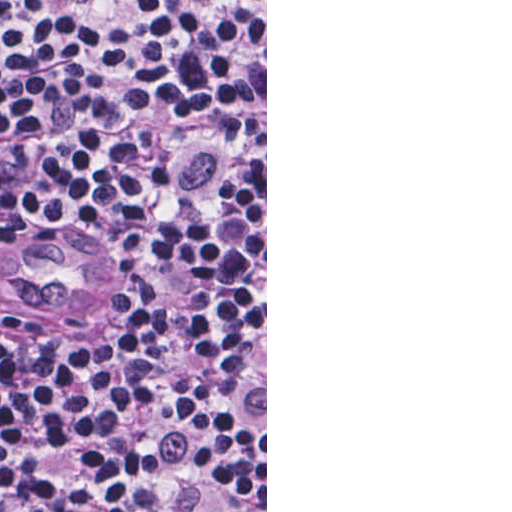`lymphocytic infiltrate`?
Here are the masks:
<instances>
[{"instance_id":"lymphocytic-infiltrate-1","label":"lymphocytic infiltrate","mask_w":512,"mask_h":512,"mask_svg":"<svg viewBox=\"0 0 512 512\" xmlns=\"http://www.w3.org/2000/svg\"><path fill=\"white\" fill-rule=\"evenodd\" d=\"M0 512H265V1H0Z\"/></svg>"}]
</instances>
